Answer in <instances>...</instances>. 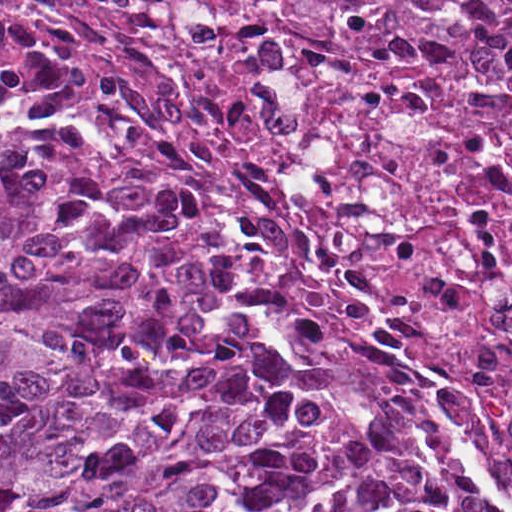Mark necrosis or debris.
<instances>
[{
  "mask_svg": "<svg viewBox=\"0 0 512 512\" xmlns=\"http://www.w3.org/2000/svg\"><path fill=\"white\" fill-rule=\"evenodd\" d=\"M0 98L122 142L284 342L512 512V1H0Z\"/></svg>",
  "mask_w": 512,
  "mask_h": 512,
  "instance_id": "necrosis-or-debris-1",
  "label": "necrosis or debris"
}]
</instances>
